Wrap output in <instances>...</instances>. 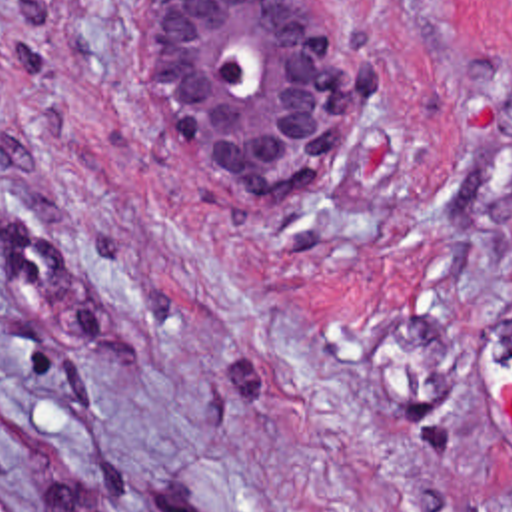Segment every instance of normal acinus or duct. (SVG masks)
<instances>
[{"label": "normal acinus or duct", "mask_w": 512, "mask_h": 512, "mask_svg": "<svg viewBox=\"0 0 512 512\" xmlns=\"http://www.w3.org/2000/svg\"><path fill=\"white\" fill-rule=\"evenodd\" d=\"M161 73L235 187L307 195L331 125L319 0H143Z\"/></svg>", "instance_id": "30e58d81"}]
</instances>
